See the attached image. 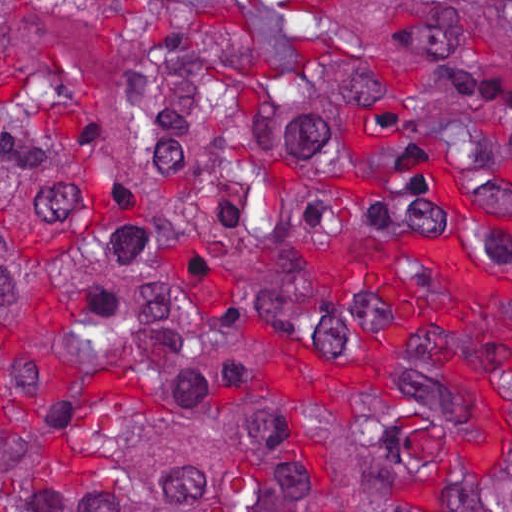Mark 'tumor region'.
<instances>
[{
	"mask_svg": "<svg viewBox=\"0 0 512 512\" xmlns=\"http://www.w3.org/2000/svg\"><path fill=\"white\" fill-rule=\"evenodd\" d=\"M0 512H512V1H0Z\"/></svg>",
	"mask_w": 512,
	"mask_h": 512,
	"instance_id": "tumor-region-1",
	"label": "tumor region"
}]
</instances>
